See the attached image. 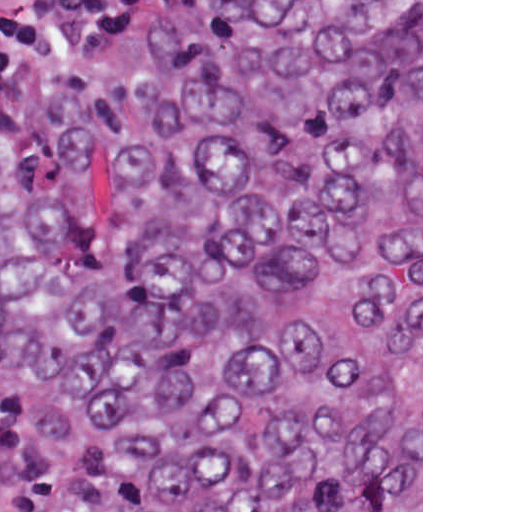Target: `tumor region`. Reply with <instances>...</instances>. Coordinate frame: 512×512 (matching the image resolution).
Masks as SVG:
<instances>
[{
    "label": "tumor region",
    "instance_id": "obj_1",
    "mask_svg": "<svg viewBox=\"0 0 512 512\" xmlns=\"http://www.w3.org/2000/svg\"><path fill=\"white\" fill-rule=\"evenodd\" d=\"M0 389L68 512H421V0H167L11 115Z\"/></svg>",
    "mask_w": 512,
    "mask_h": 512
}]
</instances>
